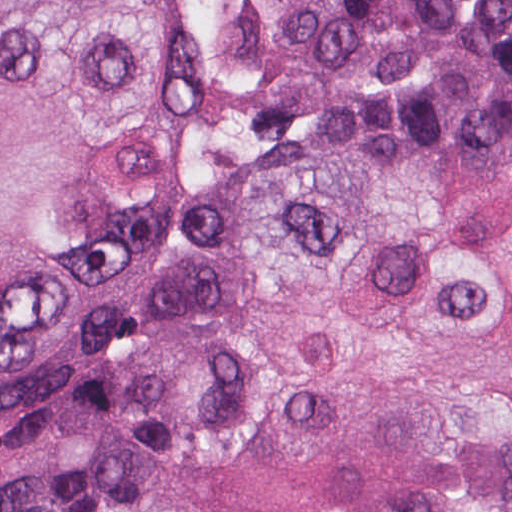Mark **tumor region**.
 Returning a JSON list of instances; mask_svg holds the SVG:
<instances>
[{
  "mask_svg": "<svg viewBox=\"0 0 512 512\" xmlns=\"http://www.w3.org/2000/svg\"><path fill=\"white\" fill-rule=\"evenodd\" d=\"M263 95L322 126L201 183L0 512H512V0H296ZM200 130L187 0H0V411L105 360Z\"/></svg>",
  "mask_w": 512,
  "mask_h": 512,
  "instance_id": "e687c5a6",
  "label": "tumor region"
}]
</instances>
